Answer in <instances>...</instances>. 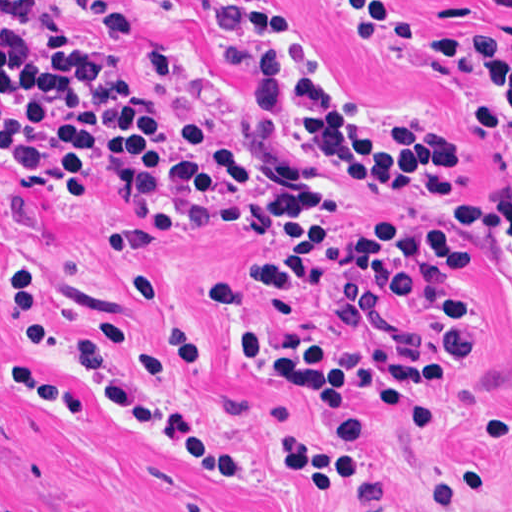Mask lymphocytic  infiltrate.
I'll return each mask as SVG.
<instances>
[{"mask_svg":"<svg viewBox=\"0 0 512 512\" xmlns=\"http://www.w3.org/2000/svg\"><path fill=\"white\" fill-rule=\"evenodd\" d=\"M47 0H0V155L32 194L78 196L128 190L160 205L172 218L248 225L269 234L248 263L211 279L206 296L218 311L242 309L243 292L260 303L258 282L280 292L328 287L354 319L348 339L291 344L264 335L240 336L256 361L286 375H260L243 361L239 341L226 347L232 369L285 395L308 421L278 446L281 475L299 476L336 493L363 469L370 424L359 406L345 425L315 412L309 381L299 376H358L398 424L440 425L443 416L410 386L441 384L460 366V334L473 315L486 350V312L470 293L463 222L512 290V199L464 200L461 156L415 128H399L384 108L365 112L378 128L351 121L326 98L301 63L313 57L304 35L256 4H231L219 28L235 56L261 74L259 101L229 107L181 104L166 98L155 75L175 73L165 51L134 32L115 7L97 21L126 55L94 61L64 27L45 16ZM512 118V39L462 41ZM0 169L12 174L0 159ZM366 179L420 197L454 218L388 211L332 212L326 183ZM138 227V226H137ZM114 231L109 260L136 265L119 245L136 228ZM129 301L147 325L134 350L133 326L111 313L88 317L87 334L59 320L41 269L9 264L8 316L15 331L95 382L108 415L164 434L199 464L242 478L248 467L194 430L149 385L198 355L200 342L170 285L131 274ZM261 305V303H260ZM258 319L254 322V325ZM51 371V370H45ZM512 425L508 407L479 427L471 458L429 489L430 512H464L474 502L488 463ZM75 432L81 426H74Z\"/></svg>","mask_w":512,"mask_h":512,"instance_id":"f902f5d3","label":"lymphocytic infiltrate"}]
</instances>
